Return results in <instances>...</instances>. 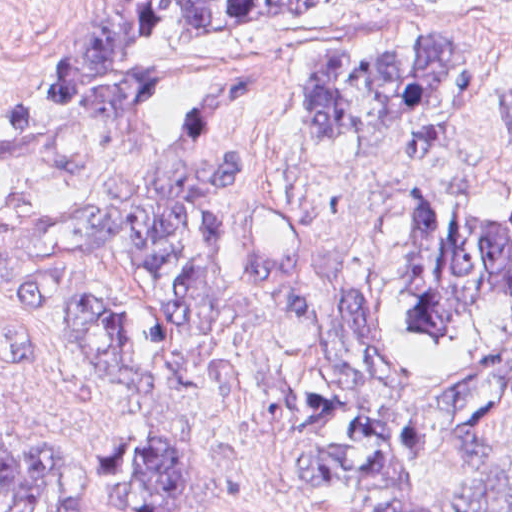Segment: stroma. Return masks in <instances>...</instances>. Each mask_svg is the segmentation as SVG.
Masks as SVG:
<instances>
[{"instance_id": "35a3bbf8", "label": "stroma", "mask_w": 512, "mask_h": 512, "mask_svg": "<svg viewBox=\"0 0 512 512\" xmlns=\"http://www.w3.org/2000/svg\"><path fill=\"white\" fill-rule=\"evenodd\" d=\"M85 1L324 3L310 33L184 95L150 136L80 158H0V210L102 207L222 154L253 173L256 189L216 215L282 214L327 282L391 317L406 183L428 195L442 221L462 187L489 212L512 211V149L498 107L512 82V0H0V103L64 63ZM441 23L458 32L466 54L468 139L437 154H408L393 134H368L337 150H320L307 137L294 101L307 45L405 40ZM77 275L124 311L132 345L159 372V389L145 402H119L72 331L36 308L0 301V429L13 451L91 460L97 491L108 497L144 488L127 469L134 443L174 451L189 496L175 512H375L387 498L434 490L512 450L511 427L381 497L293 478L280 472L290 455L282 383L303 354V336L277 298L260 289L208 334L192 336L112 252L88 256ZM399 337L402 370L417 379L438 375L512 346V307L474 315L458 344Z\"/></svg>"}]
</instances>
